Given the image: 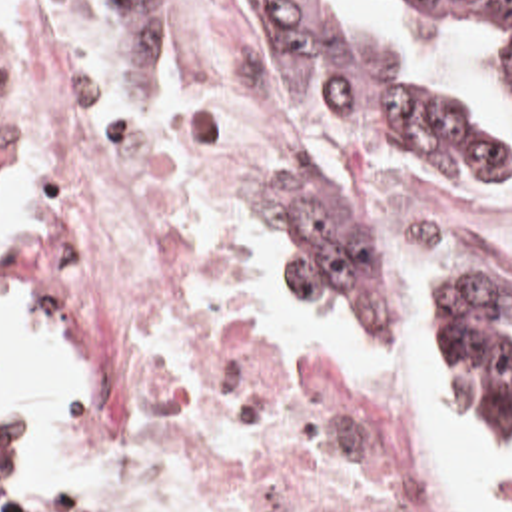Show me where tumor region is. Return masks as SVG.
I'll list each match as a JSON object with an SVG mask.
<instances>
[{"instance_id": "obj_1", "label": "tumor region", "mask_w": 512, "mask_h": 512, "mask_svg": "<svg viewBox=\"0 0 512 512\" xmlns=\"http://www.w3.org/2000/svg\"><path fill=\"white\" fill-rule=\"evenodd\" d=\"M257 1L285 35L305 85L337 121L375 131L444 171H512V105L500 131L466 133L407 85L325 43L307 25L313 0ZM430 1L484 17L512 15V0ZM502 69L512 97V43ZM261 219L289 283L341 321H375V245L347 229L355 219L325 209L301 183H261ZM407 313L438 406L484 412L502 350L512 346V281L426 279Z\"/></svg>"}]
</instances>
